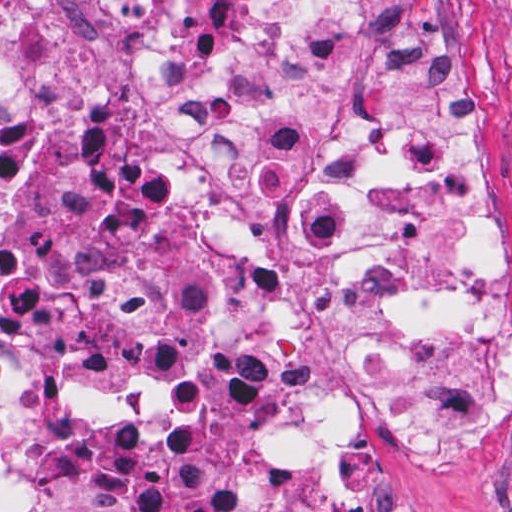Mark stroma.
Wrapping results in <instances>:
<instances>
[{"instance_id": "stroma-1", "label": "stroma", "mask_w": 512, "mask_h": 512, "mask_svg": "<svg viewBox=\"0 0 512 512\" xmlns=\"http://www.w3.org/2000/svg\"><path fill=\"white\" fill-rule=\"evenodd\" d=\"M458 4L454 91L478 175L477 204L495 223L508 332L505 424L444 496L397 465L389 436L362 435L350 492L362 512H512V0Z\"/></svg>"}]
</instances>
